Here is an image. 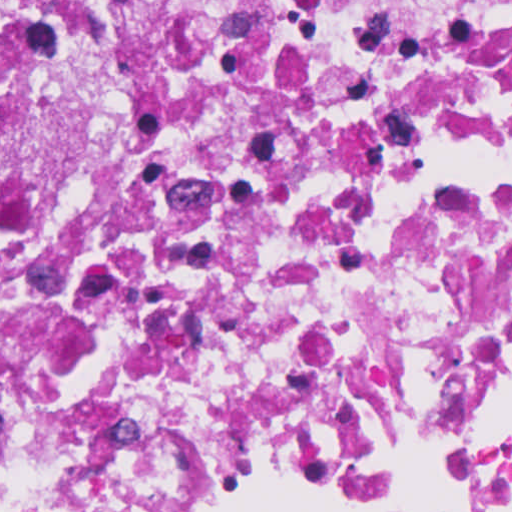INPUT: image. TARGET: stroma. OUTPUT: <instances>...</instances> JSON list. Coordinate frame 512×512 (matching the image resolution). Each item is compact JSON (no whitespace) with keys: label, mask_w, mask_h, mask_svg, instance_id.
<instances>
[{"label":"stroma","mask_w":512,"mask_h":512,"mask_svg":"<svg viewBox=\"0 0 512 512\" xmlns=\"http://www.w3.org/2000/svg\"><path fill=\"white\" fill-rule=\"evenodd\" d=\"M183 501V500H182ZM182 501L173 506V512L181 505ZM240 512H299L291 509H286L278 506H249Z\"/></svg>","instance_id":"obj_1"}]
</instances>
